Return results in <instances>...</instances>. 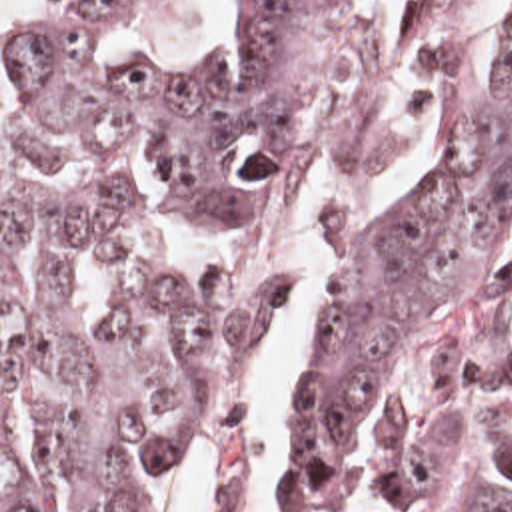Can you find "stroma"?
Masks as SVG:
<instances>
[{
  "label": "stroma",
  "mask_w": 512,
  "mask_h": 512,
  "mask_svg": "<svg viewBox=\"0 0 512 512\" xmlns=\"http://www.w3.org/2000/svg\"><path fill=\"white\" fill-rule=\"evenodd\" d=\"M396 103H420V0H348L318 69V105L344 159Z\"/></svg>",
  "instance_id": "35a3bbf8"
}]
</instances>
